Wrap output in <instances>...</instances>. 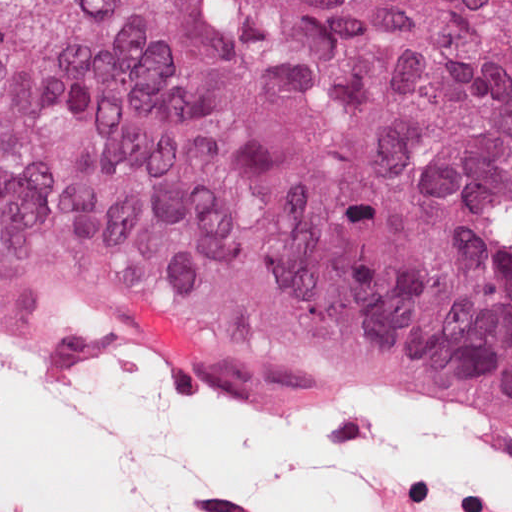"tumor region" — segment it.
<instances>
[{
    "instance_id": "e687c5a6",
    "label": "tumor region",
    "mask_w": 512,
    "mask_h": 512,
    "mask_svg": "<svg viewBox=\"0 0 512 512\" xmlns=\"http://www.w3.org/2000/svg\"><path fill=\"white\" fill-rule=\"evenodd\" d=\"M0 298L512 429V0H0Z\"/></svg>"
}]
</instances>
